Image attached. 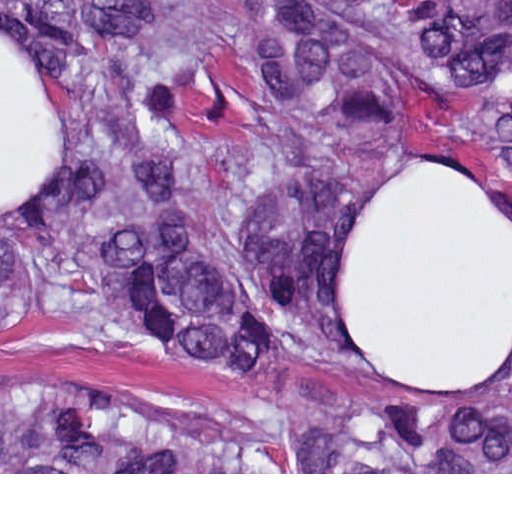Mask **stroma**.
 <instances>
[{"label": "stroma", "instance_id": "1", "mask_svg": "<svg viewBox=\"0 0 512 512\" xmlns=\"http://www.w3.org/2000/svg\"><path fill=\"white\" fill-rule=\"evenodd\" d=\"M0 24L33 58L63 115V171L34 201L0 205V223H41L75 191L64 133V86L49 35L26 0H0ZM452 165V164H450ZM454 166V165H453ZM456 167V166H455ZM53 381L107 396L167 424L231 440L261 457L281 415L319 408L287 386L256 383L187 362L143 355L81 321L0 328V394ZM0 474H512V472H0Z\"/></svg>", "mask_w": 512, "mask_h": 512}]
</instances>
